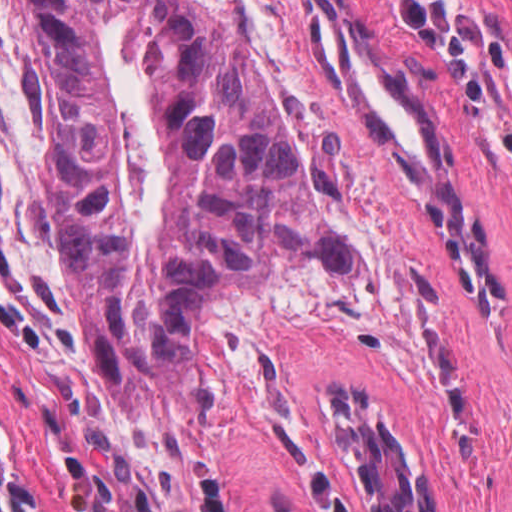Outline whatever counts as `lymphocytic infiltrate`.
Wrapping results in <instances>:
<instances>
[{"label":"lymphocytic infiltrate","instance_id":"lymphocytic-infiltrate-1","mask_svg":"<svg viewBox=\"0 0 512 512\" xmlns=\"http://www.w3.org/2000/svg\"><path fill=\"white\" fill-rule=\"evenodd\" d=\"M395 24L416 47L452 67L468 113L492 110V91L451 13L431 0H386Z\"/></svg>","mask_w":512,"mask_h":512}]
</instances>
